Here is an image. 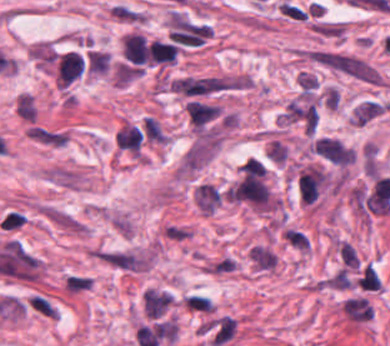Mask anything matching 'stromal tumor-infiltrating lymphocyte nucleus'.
I'll return each mask as SVG.
<instances>
[{
	"mask_svg": "<svg viewBox=\"0 0 390 346\" xmlns=\"http://www.w3.org/2000/svg\"><path fill=\"white\" fill-rule=\"evenodd\" d=\"M125 60L132 64H145L146 39L141 33H128L124 37Z\"/></svg>",
	"mask_w": 390,
	"mask_h": 346,
	"instance_id": "abfb95fc",
	"label": "stromal tumor-infiltrating lymphocyte nucleus"
},
{
	"mask_svg": "<svg viewBox=\"0 0 390 346\" xmlns=\"http://www.w3.org/2000/svg\"><path fill=\"white\" fill-rule=\"evenodd\" d=\"M84 72V52L69 49L57 53L54 59L53 74L59 88H67Z\"/></svg>",
	"mask_w": 390,
	"mask_h": 346,
	"instance_id": "bc302bb0",
	"label": "stromal tumor-infiltrating lymphocyte nucleus"
},
{
	"mask_svg": "<svg viewBox=\"0 0 390 346\" xmlns=\"http://www.w3.org/2000/svg\"><path fill=\"white\" fill-rule=\"evenodd\" d=\"M116 148L133 155H140L144 141L139 124L124 123L114 137Z\"/></svg>",
	"mask_w": 390,
	"mask_h": 346,
	"instance_id": "52c7bb5b",
	"label": "stromal tumor-infiltrating lymphocyte nucleus"
},
{
	"mask_svg": "<svg viewBox=\"0 0 390 346\" xmlns=\"http://www.w3.org/2000/svg\"><path fill=\"white\" fill-rule=\"evenodd\" d=\"M177 51L173 43L152 39L147 51V63L173 64Z\"/></svg>",
	"mask_w": 390,
	"mask_h": 346,
	"instance_id": "3290ff9b",
	"label": "stromal tumor-infiltrating lymphocyte nucleus"
}]
</instances>
